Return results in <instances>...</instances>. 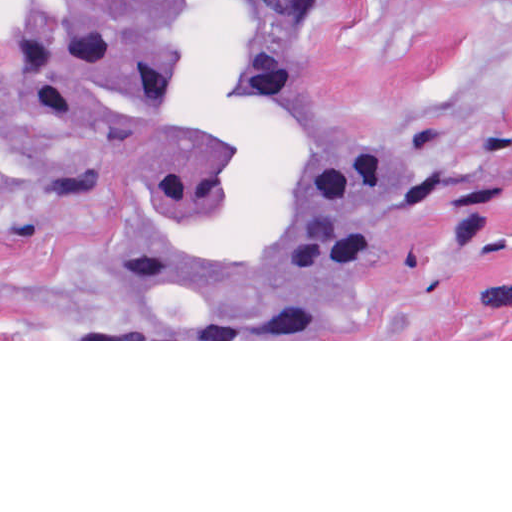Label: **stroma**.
I'll use <instances>...</instances> for the list:
<instances>
[{
	"mask_svg": "<svg viewBox=\"0 0 512 512\" xmlns=\"http://www.w3.org/2000/svg\"><path fill=\"white\" fill-rule=\"evenodd\" d=\"M302 106L427 158L418 217L266 315L155 300L88 199L0 146V341H512V0H315Z\"/></svg>",
	"mask_w": 512,
	"mask_h": 512,
	"instance_id": "stroma-1",
	"label": "stroma"
}]
</instances>
